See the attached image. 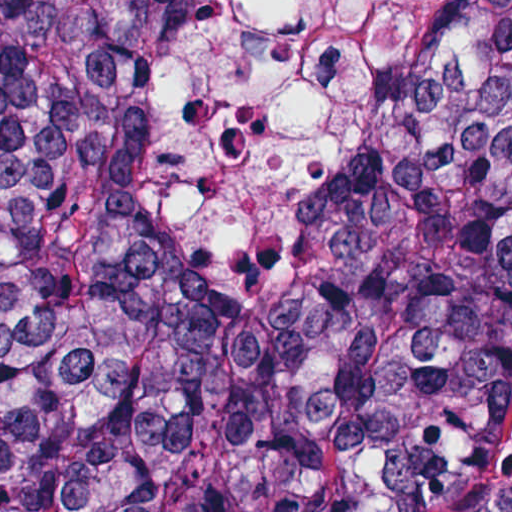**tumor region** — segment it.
<instances>
[{
	"instance_id": "e687c5a6",
	"label": "tumor region",
	"mask_w": 512,
	"mask_h": 512,
	"mask_svg": "<svg viewBox=\"0 0 512 512\" xmlns=\"http://www.w3.org/2000/svg\"><path fill=\"white\" fill-rule=\"evenodd\" d=\"M217 1L4 2L0 512H446L512 402V0L255 268L170 242L140 169Z\"/></svg>"
}]
</instances>
